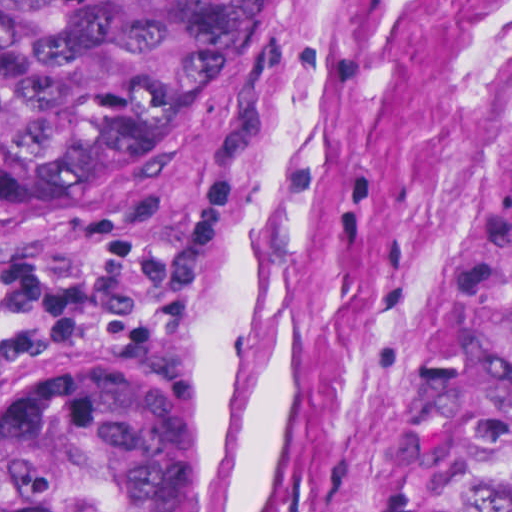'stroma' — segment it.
Wrapping results in <instances>:
<instances>
[{
    "label": "stroma",
    "mask_w": 512,
    "mask_h": 512,
    "mask_svg": "<svg viewBox=\"0 0 512 512\" xmlns=\"http://www.w3.org/2000/svg\"><path fill=\"white\" fill-rule=\"evenodd\" d=\"M196 170L236 187L209 309L142 362L183 391V512H405L452 304L512 182V0H293L273 65L0 262L95 247ZM26 369V370H27Z\"/></svg>",
    "instance_id": "1"
}]
</instances>
